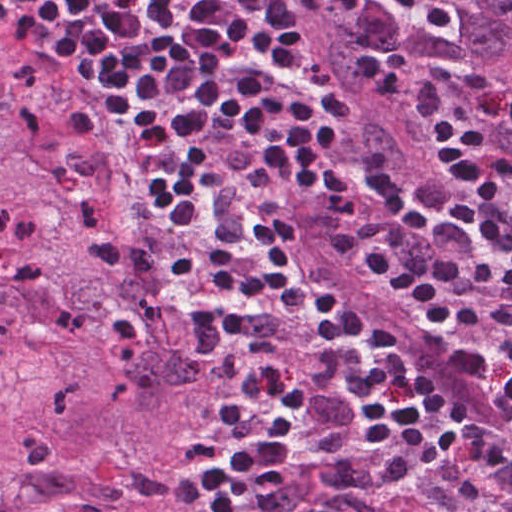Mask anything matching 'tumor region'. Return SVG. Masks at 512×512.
Here are the masks:
<instances>
[{"mask_svg": "<svg viewBox=\"0 0 512 512\" xmlns=\"http://www.w3.org/2000/svg\"><path fill=\"white\" fill-rule=\"evenodd\" d=\"M512 76V0H427Z\"/></svg>", "mask_w": 512, "mask_h": 512, "instance_id": "1", "label": "tumor region"}]
</instances>
